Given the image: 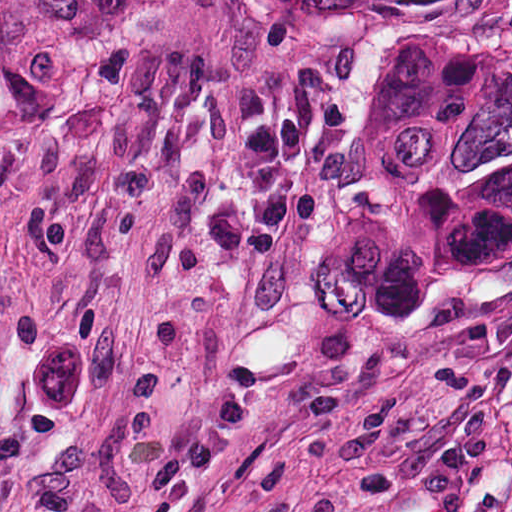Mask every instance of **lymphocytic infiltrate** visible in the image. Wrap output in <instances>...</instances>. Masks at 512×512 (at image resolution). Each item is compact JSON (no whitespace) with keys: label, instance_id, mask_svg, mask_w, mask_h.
Here are the masks:
<instances>
[{"label":"lymphocytic infiltrate","instance_id":"lymphocytic-infiltrate-1","mask_svg":"<svg viewBox=\"0 0 512 512\" xmlns=\"http://www.w3.org/2000/svg\"><path fill=\"white\" fill-rule=\"evenodd\" d=\"M305 149L307 140L297 118L285 119L261 130L237 164L236 183L249 210L250 260H265L275 253L293 191L289 163Z\"/></svg>","mask_w":512,"mask_h":512}]
</instances>
